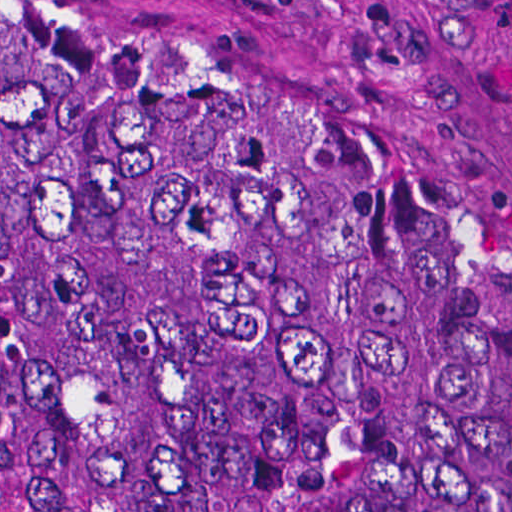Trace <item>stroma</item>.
<instances>
[{
  "instance_id": "obj_1",
  "label": "stroma",
  "mask_w": 512,
  "mask_h": 512,
  "mask_svg": "<svg viewBox=\"0 0 512 512\" xmlns=\"http://www.w3.org/2000/svg\"><path fill=\"white\" fill-rule=\"evenodd\" d=\"M82 1L211 52L512 319V0Z\"/></svg>"
}]
</instances>
